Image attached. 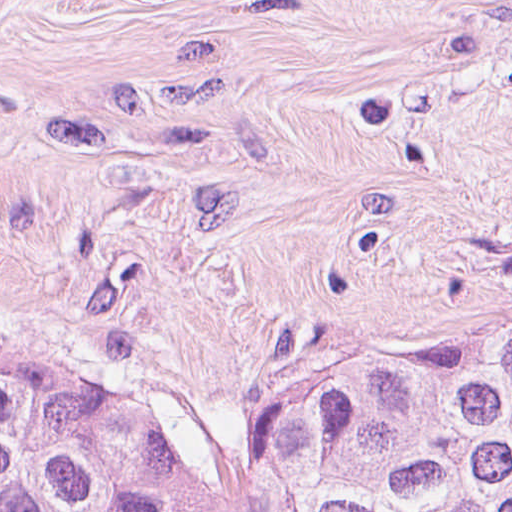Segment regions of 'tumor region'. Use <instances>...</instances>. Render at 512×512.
Listing matches in <instances>:
<instances>
[{
    "label": "tumor region",
    "mask_w": 512,
    "mask_h": 512,
    "mask_svg": "<svg viewBox=\"0 0 512 512\" xmlns=\"http://www.w3.org/2000/svg\"><path fill=\"white\" fill-rule=\"evenodd\" d=\"M0 512H512V327L208 461L52 369L0 361Z\"/></svg>",
    "instance_id": "obj_1"
}]
</instances>
